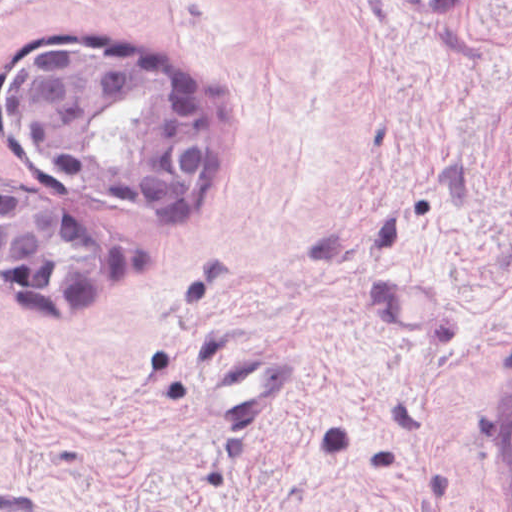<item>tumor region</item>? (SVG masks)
I'll return each instance as SVG.
<instances>
[{"label":"tumor region","instance_id":"1","mask_svg":"<svg viewBox=\"0 0 512 512\" xmlns=\"http://www.w3.org/2000/svg\"><path fill=\"white\" fill-rule=\"evenodd\" d=\"M2 83L16 136L75 173L141 199H184L215 163V102L186 65L109 35L34 37ZM139 239L66 200L0 183V293L39 312H83L137 259ZM512 465V390L508 403Z\"/></svg>","mask_w":512,"mask_h":512}]
</instances>
